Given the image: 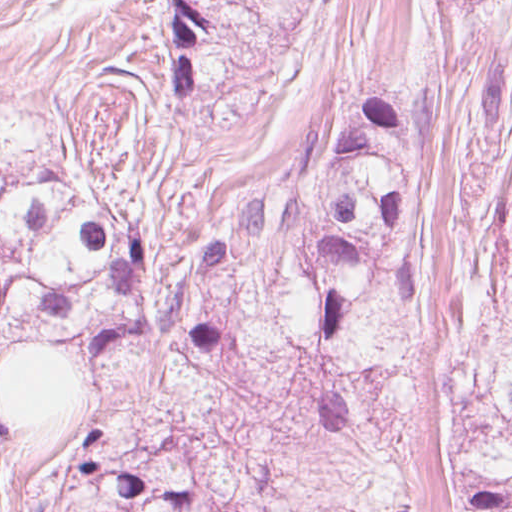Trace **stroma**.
<instances>
[{
	"mask_svg": "<svg viewBox=\"0 0 512 512\" xmlns=\"http://www.w3.org/2000/svg\"><path fill=\"white\" fill-rule=\"evenodd\" d=\"M205 23L195 83L168 81L165 0H0V167L103 185L153 234L139 339L83 362L17 337L0 379L53 348L81 397L0 421V512H27L70 443L116 427L175 441L219 502L244 512H449L447 398L505 281L512 232V0H190ZM408 103L424 120L419 269L428 284L410 403L364 428L313 419L301 362L193 372L168 306L200 225L317 160L341 106Z\"/></svg>",
	"mask_w": 512,
	"mask_h": 512,
	"instance_id": "35a3bbf8",
	"label": "stroma"
}]
</instances>
